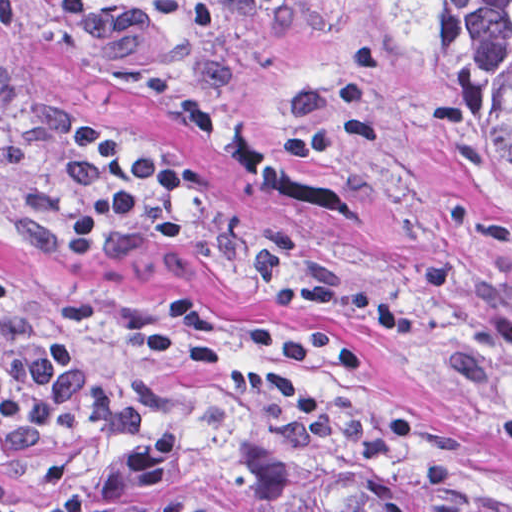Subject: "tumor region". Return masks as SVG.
<instances>
[{"label":"tumor region","instance_id":"tumor-region-1","mask_svg":"<svg viewBox=\"0 0 512 512\" xmlns=\"http://www.w3.org/2000/svg\"><path fill=\"white\" fill-rule=\"evenodd\" d=\"M444 75L512 173V0H405ZM13 115L0 85V138ZM102 512H422L347 482L306 494L276 467L188 437H149L101 474Z\"/></svg>","mask_w":512,"mask_h":512}]
</instances>
